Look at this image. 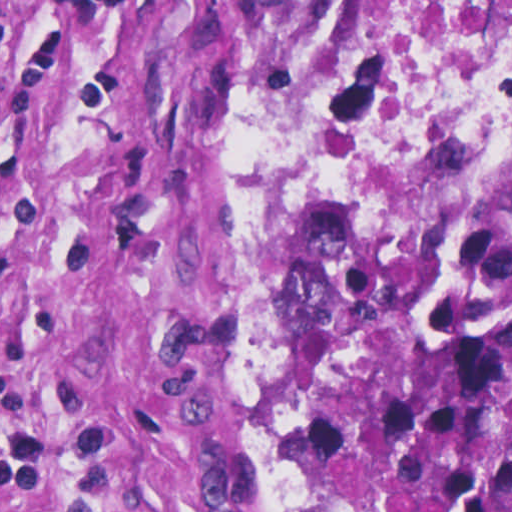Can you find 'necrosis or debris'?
<instances>
[{
    "label": "necrosis or debris",
    "mask_w": 512,
    "mask_h": 512,
    "mask_svg": "<svg viewBox=\"0 0 512 512\" xmlns=\"http://www.w3.org/2000/svg\"><path fill=\"white\" fill-rule=\"evenodd\" d=\"M310 130L329 141L512 135V0H339Z\"/></svg>",
    "instance_id": "4bbe7bcc"
}]
</instances>
